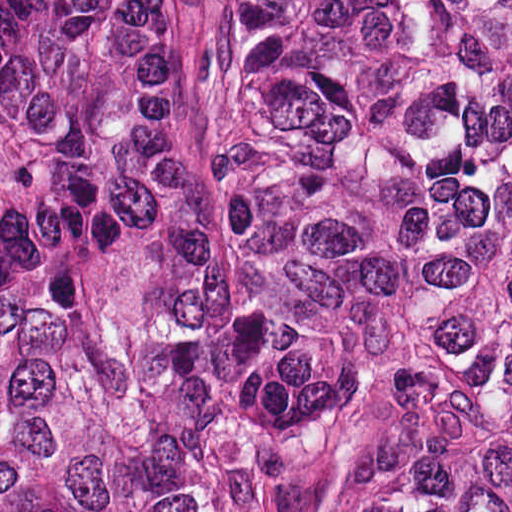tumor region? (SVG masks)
<instances>
[{
  "instance_id": "obj_1",
  "label": "tumor region",
  "mask_w": 512,
  "mask_h": 512,
  "mask_svg": "<svg viewBox=\"0 0 512 512\" xmlns=\"http://www.w3.org/2000/svg\"><path fill=\"white\" fill-rule=\"evenodd\" d=\"M228 202L170 0H0V512H512V0L213 1Z\"/></svg>"
}]
</instances>
